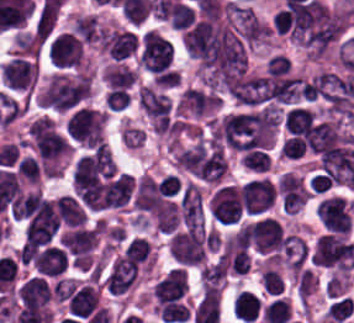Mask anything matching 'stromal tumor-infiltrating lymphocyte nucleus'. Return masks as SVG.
<instances>
[{
  "label": "stromal tumor-infiltrating lymphocyte nucleus",
  "mask_w": 354,
  "mask_h": 323,
  "mask_svg": "<svg viewBox=\"0 0 354 323\" xmlns=\"http://www.w3.org/2000/svg\"><path fill=\"white\" fill-rule=\"evenodd\" d=\"M34 73L33 58L17 54L0 68V82L8 92H26L34 83Z\"/></svg>",
  "instance_id": "stromal-tumor-infiltrating-lymphocyte-nucleus-1"
},
{
  "label": "stromal tumor-infiltrating lymphocyte nucleus",
  "mask_w": 354,
  "mask_h": 323,
  "mask_svg": "<svg viewBox=\"0 0 354 323\" xmlns=\"http://www.w3.org/2000/svg\"><path fill=\"white\" fill-rule=\"evenodd\" d=\"M168 15L173 27H186L195 19V13L190 6L176 1L169 9Z\"/></svg>",
  "instance_id": "stromal-tumor-infiltrating-lymphocyte-nucleus-3"
},
{
  "label": "stromal tumor-infiltrating lymphocyte nucleus",
  "mask_w": 354,
  "mask_h": 323,
  "mask_svg": "<svg viewBox=\"0 0 354 323\" xmlns=\"http://www.w3.org/2000/svg\"><path fill=\"white\" fill-rule=\"evenodd\" d=\"M47 52L53 65H79L81 42L69 32H62L49 42Z\"/></svg>",
  "instance_id": "stromal-tumor-infiltrating-lymphocyte-nucleus-2"
}]
</instances>
